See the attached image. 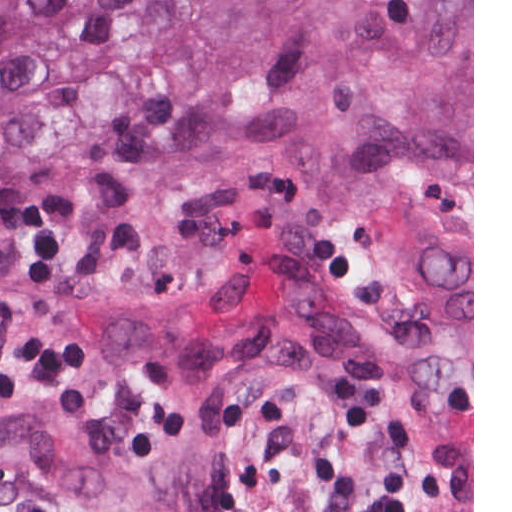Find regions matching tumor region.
Returning <instances> with one entry per match:
<instances>
[{
  "instance_id": "e687c5a6",
  "label": "tumor region",
  "mask_w": 512,
  "mask_h": 512,
  "mask_svg": "<svg viewBox=\"0 0 512 512\" xmlns=\"http://www.w3.org/2000/svg\"><path fill=\"white\" fill-rule=\"evenodd\" d=\"M267 361L362 390L369 512H473V0H0V470L239 512Z\"/></svg>"
}]
</instances>
